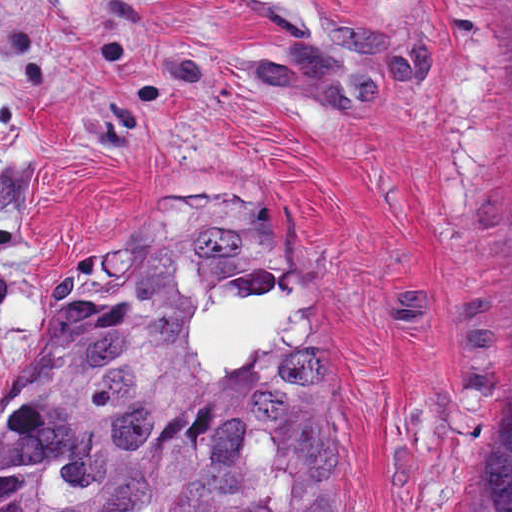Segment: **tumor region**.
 Masks as SVG:
<instances>
[{
  "instance_id": "obj_1",
  "label": "tumor region",
  "mask_w": 512,
  "mask_h": 512,
  "mask_svg": "<svg viewBox=\"0 0 512 512\" xmlns=\"http://www.w3.org/2000/svg\"><path fill=\"white\" fill-rule=\"evenodd\" d=\"M294 268L275 235L132 228L0 403V512H357L327 337L297 309L228 375L186 337L214 299L292 293ZM462 470L464 512H512V260Z\"/></svg>"
}]
</instances>
